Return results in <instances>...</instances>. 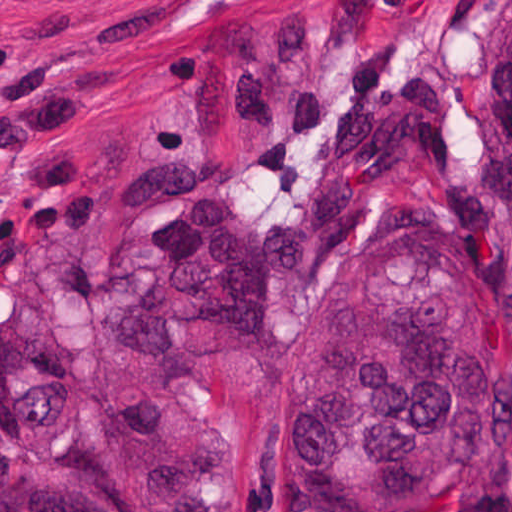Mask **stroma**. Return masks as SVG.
<instances>
[{"mask_svg": "<svg viewBox=\"0 0 512 512\" xmlns=\"http://www.w3.org/2000/svg\"><path fill=\"white\" fill-rule=\"evenodd\" d=\"M496 1L0 0V491L75 476L13 424L18 386L51 382L108 462H187L209 512H293V344L399 226L473 182L497 211L477 72ZM156 153L199 155L267 227L340 178L359 237L280 282L263 343L180 325L173 352H124L108 303L144 290L140 233L166 206L126 186ZM435 512H512V463Z\"/></svg>", "mask_w": 512, "mask_h": 512, "instance_id": "35a3bbf8", "label": "stroma"}]
</instances>
